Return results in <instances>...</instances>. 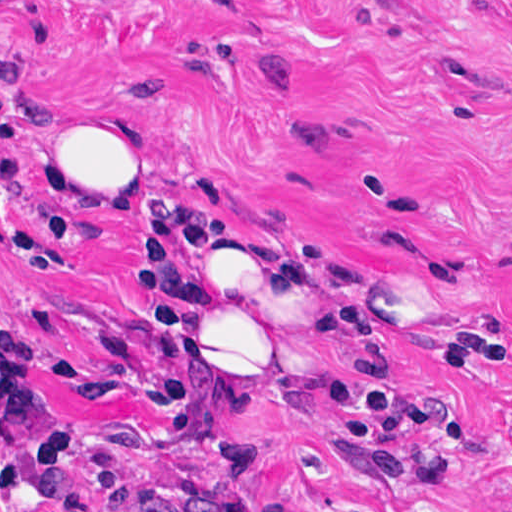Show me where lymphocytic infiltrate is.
<instances>
[{"mask_svg":"<svg viewBox=\"0 0 512 512\" xmlns=\"http://www.w3.org/2000/svg\"><path fill=\"white\" fill-rule=\"evenodd\" d=\"M9 18L0 14V30ZM138 201V290L147 302V349L135 370V397L159 406L187 442L212 456L222 480L211 489L129 488L117 461L94 466L104 498L93 504L76 477L86 447L69 406L38 385L39 332L0 321V512H248L240 490L252 449L227 428V416L248 405L231 392L206 356L171 338L163 322L166 293L178 260L208 240L219 212L264 200L254 161L212 145L194 153L166 182H135ZM59 235H75L72 210L44 204ZM375 473L402 480L411 467L402 437L418 424L415 405L399 392L341 394L334 411Z\"/></svg>","mask_w":512,"mask_h":512,"instance_id":"1","label":"lymphocytic infiltrate"}]
</instances>
